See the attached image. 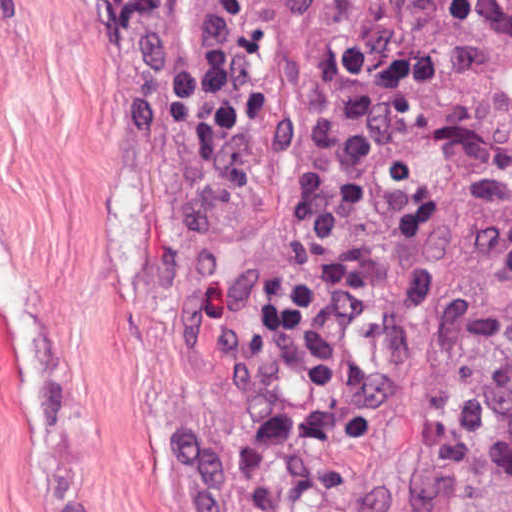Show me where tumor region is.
Returning a JSON list of instances; mask_svg holds the SVG:
<instances>
[{
    "label": "tumor region",
    "instance_id": "tumor-region-1",
    "mask_svg": "<svg viewBox=\"0 0 512 512\" xmlns=\"http://www.w3.org/2000/svg\"><path fill=\"white\" fill-rule=\"evenodd\" d=\"M459 512H512V489L467 504Z\"/></svg>",
    "mask_w": 512,
    "mask_h": 512
}]
</instances>
